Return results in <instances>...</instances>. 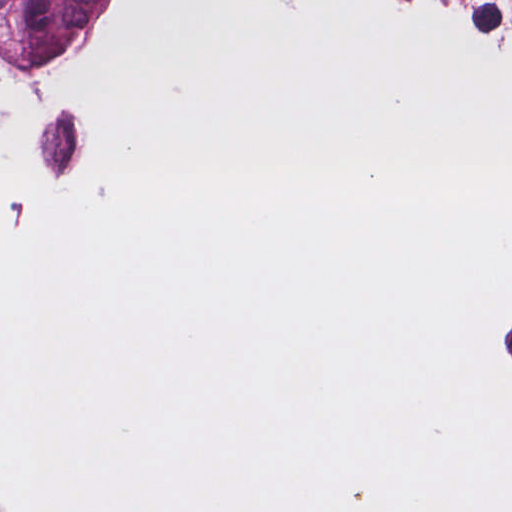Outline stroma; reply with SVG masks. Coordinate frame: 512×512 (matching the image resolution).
<instances>
[{"label":"stroma","mask_w":512,"mask_h":512,"mask_svg":"<svg viewBox=\"0 0 512 512\" xmlns=\"http://www.w3.org/2000/svg\"><path fill=\"white\" fill-rule=\"evenodd\" d=\"M166 0H136L130 35L113 63L92 78L59 79L0 69V110L37 91L110 96L132 89L158 57ZM439 30L451 43L502 53L512 42V0H426ZM10 312L0 279V319Z\"/></svg>","instance_id":"1"}]
</instances>
